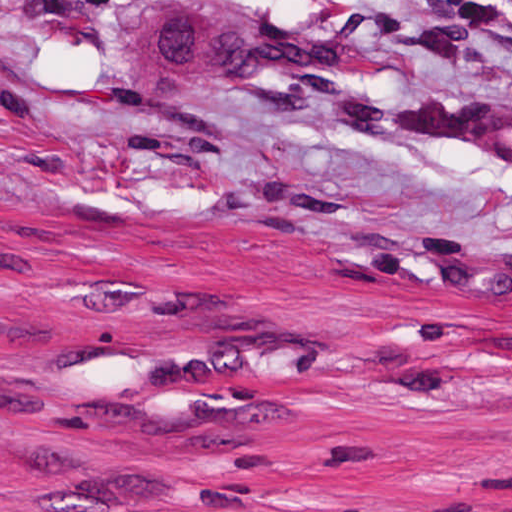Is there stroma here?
Wrapping results in <instances>:
<instances>
[{"instance_id": "1", "label": "stroma", "mask_w": 512, "mask_h": 512, "mask_svg": "<svg viewBox=\"0 0 512 512\" xmlns=\"http://www.w3.org/2000/svg\"><path fill=\"white\" fill-rule=\"evenodd\" d=\"M0 512H512V0H0Z\"/></svg>"}]
</instances>
